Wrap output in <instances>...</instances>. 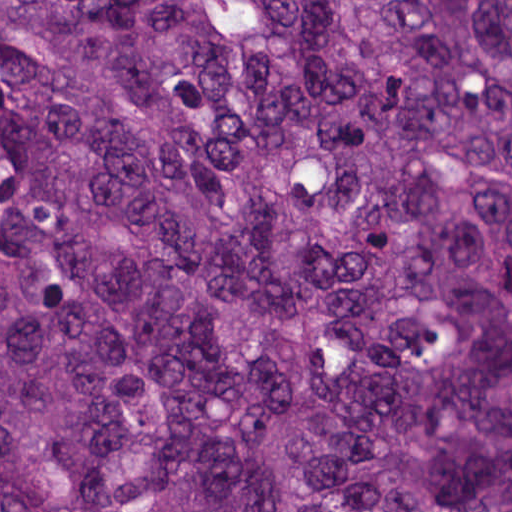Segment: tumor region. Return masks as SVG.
Masks as SVG:
<instances>
[{
  "instance_id": "e687c5a6",
  "label": "tumor region",
  "mask_w": 512,
  "mask_h": 512,
  "mask_svg": "<svg viewBox=\"0 0 512 512\" xmlns=\"http://www.w3.org/2000/svg\"><path fill=\"white\" fill-rule=\"evenodd\" d=\"M0 512H512V0H0Z\"/></svg>"
}]
</instances>
